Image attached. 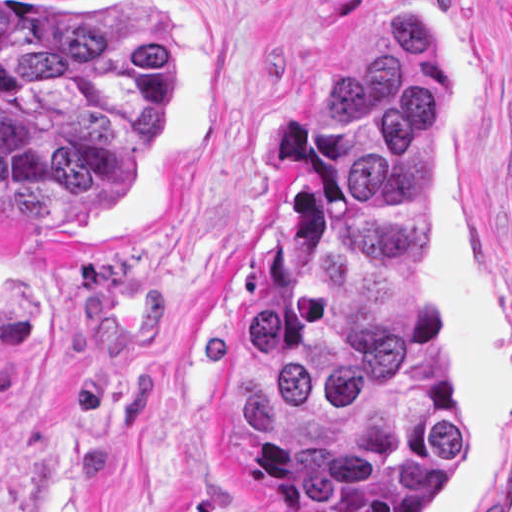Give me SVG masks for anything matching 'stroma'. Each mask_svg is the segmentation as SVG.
<instances>
[{
    "mask_svg": "<svg viewBox=\"0 0 512 512\" xmlns=\"http://www.w3.org/2000/svg\"><path fill=\"white\" fill-rule=\"evenodd\" d=\"M105 1L171 43L113 209L0 201V512H296L224 472L215 356L259 292L325 83L401 9L444 86L430 327L464 411L434 512H512V0Z\"/></svg>",
    "mask_w": 512,
    "mask_h": 512,
    "instance_id": "35a3bbf8",
    "label": "stroma"
}]
</instances>
